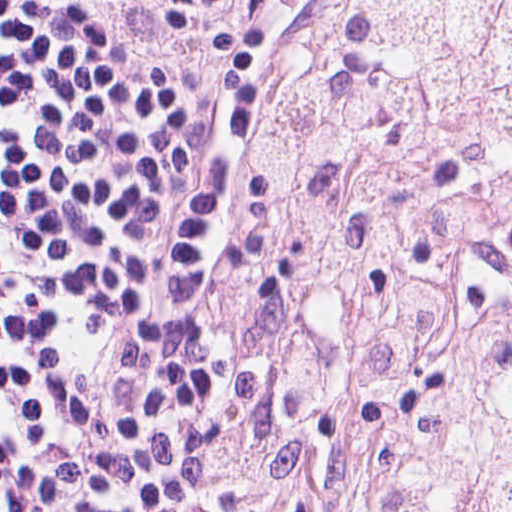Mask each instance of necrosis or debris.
I'll use <instances>...</instances> for the list:
<instances>
[{"mask_svg": "<svg viewBox=\"0 0 512 512\" xmlns=\"http://www.w3.org/2000/svg\"><path fill=\"white\" fill-rule=\"evenodd\" d=\"M277 512H512V0H328L264 150Z\"/></svg>", "mask_w": 512, "mask_h": 512, "instance_id": "4bbe7bcc", "label": "necrosis or debris"}]
</instances>
